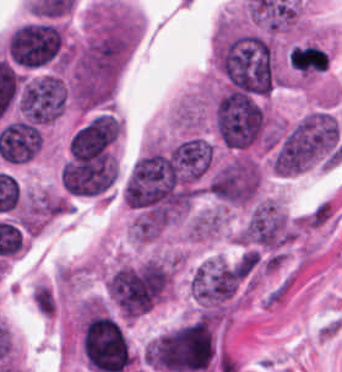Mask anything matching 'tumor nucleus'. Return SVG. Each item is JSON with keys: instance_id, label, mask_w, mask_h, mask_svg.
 Listing matches in <instances>:
<instances>
[{"instance_id": "tumor-nucleus-1", "label": "tumor nucleus", "mask_w": 342, "mask_h": 372, "mask_svg": "<svg viewBox=\"0 0 342 372\" xmlns=\"http://www.w3.org/2000/svg\"><path fill=\"white\" fill-rule=\"evenodd\" d=\"M66 51L63 26L53 20H34L20 25L7 38L8 59L23 69L65 64Z\"/></svg>"}, {"instance_id": "tumor-nucleus-2", "label": "tumor nucleus", "mask_w": 342, "mask_h": 372, "mask_svg": "<svg viewBox=\"0 0 342 372\" xmlns=\"http://www.w3.org/2000/svg\"><path fill=\"white\" fill-rule=\"evenodd\" d=\"M263 169L253 152H234L209 174L207 190L228 205H247L256 197Z\"/></svg>"}]
</instances>
